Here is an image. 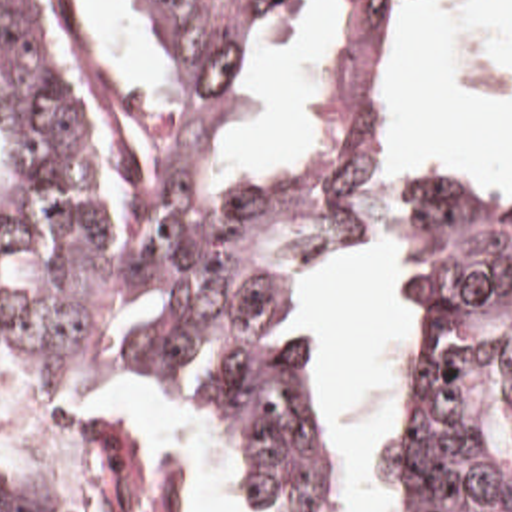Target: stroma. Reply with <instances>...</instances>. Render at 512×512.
<instances>
[{
    "label": "stroma",
    "instance_id": "35a3bbf8",
    "mask_svg": "<svg viewBox=\"0 0 512 512\" xmlns=\"http://www.w3.org/2000/svg\"><path fill=\"white\" fill-rule=\"evenodd\" d=\"M422 0H395V20L373 62L367 90L359 102V228H375V202L381 182L393 164L415 160L432 168L468 190L492 196H512V174L498 186L472 184L448 168L417 152L389 122L387 96L397 80L401 62L409 50ZM309 358L311 348L303 334ZM139 390H179L191 394L203 406L215 410L223 430V458L231 477L233 511L251 512L243 479L237 468V424L233 404L221 382L213 376H137L121 386V512H183L181 509V448L179 440L167 436L157 454L147 464L141 456L135 414L131 410L133 392ZM0 412L13 436L17 450L0 456V473L29 471L37 458V432L29 404L17 380L0 364ZM345 464V462H343ZM347 471V469H345Z\"/></svg>",
    "mask_w": 512,
    "mask_h": 512
}]
</instances>
